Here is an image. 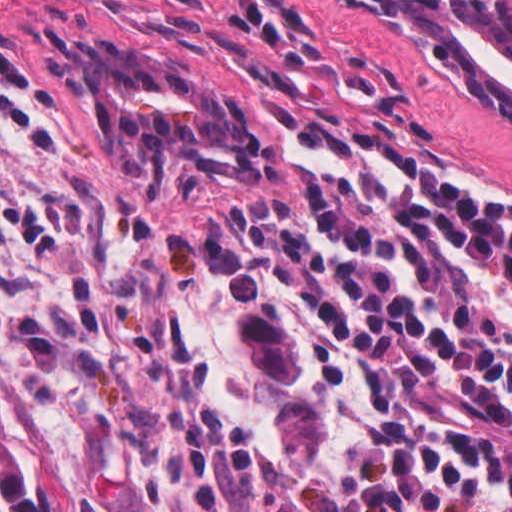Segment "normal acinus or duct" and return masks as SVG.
Listing matches in <instances>:
<instances>
[{"label":"normal acinus or duct","instance_id":"normal-acinus-or-duct-1","mask_svg":"<svg viewBox=\"0 0 512 512\" xmlns=\"http://www.w3.org/2000/svg\"><path fill=\"white\" fill-rule=\"evenodd\" d=\"M363 15L427 88L512 129V5L505 0H338Z\"/></svg>","mask_w":512,"mask_h":512}]
</instances>
